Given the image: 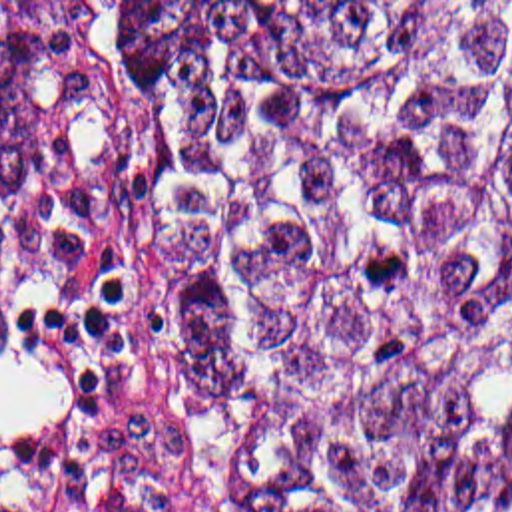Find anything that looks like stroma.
<instances>
[{"label":"stroma","instance_id":"1","mask_svg":"<svg viewBox=\"0 0 512 512\" xmlns=\"http://www.w3.org/2000/svg\"><path fill=\"white\" fill-rule=\"evenodd\" d=\"M110 2L512 0H0V18L86 12V52L54 86L48 197L0 199V512H207L132 341L156 108Z\"/></svg>","mask_w":512,"mask_h":512}]
</instances>
